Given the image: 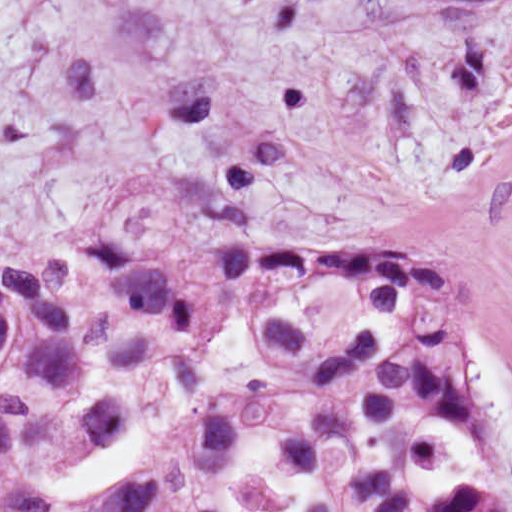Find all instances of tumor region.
Segmentation results:
<instances>
[{
	"label": "tumor region",
	"instance_id": "obj_1",
	"mask_svg": "<svg viewBox=\"0 0 512 512\" xmlns=\"http://www.w3.org/2000/svg\"><path fill=\"white\" fill-rule=\"evenodd\" d=\"M200 203L0 269V512H512L424 257Z\"/></svg>",
	"mask_w": 512,
	"mask_h": 512
}]
</instances>
